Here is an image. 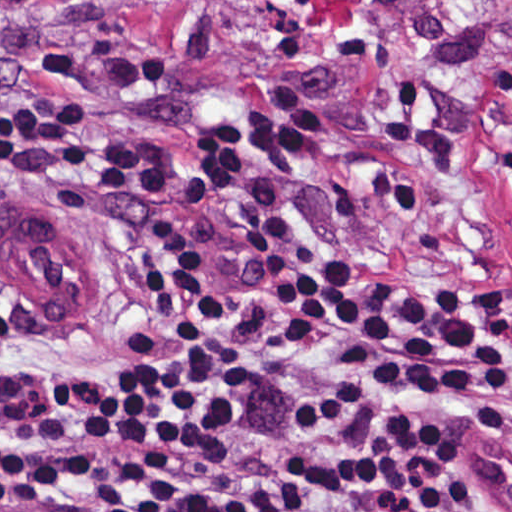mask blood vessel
I'll use <instances>...</instances> for the list:
<instances>
[{"mask_svg":"<svg viewBox=\"0 0 512 512\" xmlns=\"http://www.w3.org/2000/svg\"><path fill=\"white\" fill-rule=\"evenodd\" d=\"M0 279L14 305L40 321L77 312L90 291V257L47 209L0 214Z\"/></svg>","mask_w":512,"mask_h":512,"instance_id":"8fb6f2fc","label":"blood vessel"}]
</instances>
